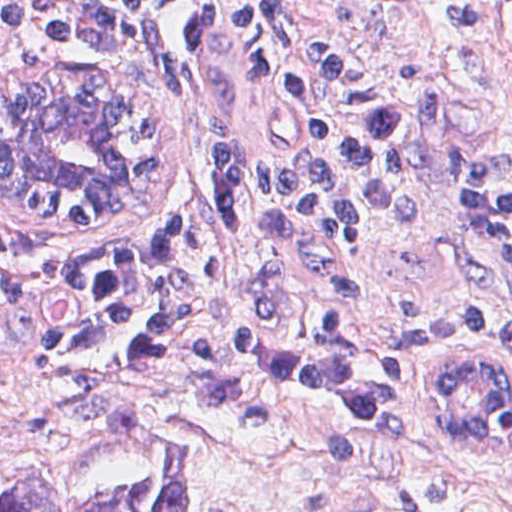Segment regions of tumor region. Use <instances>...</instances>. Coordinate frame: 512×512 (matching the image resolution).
I'll return each instance as SVG.
<instances>
[{"label":"tumor region","mask_w":512,"mask_h":512,"mask_svg":"<svg viewBox=\"0 0 512 512\" xmlns=\"http://www.w3.org/2000/svg\"><path fill=\"white\" fill-rule=\"evenodd\" d=\"M189 481L187 450L123 403L91 453L0 478V512H190Z\"/></svg>","instance_id":"obj_1"}]
</instances>
